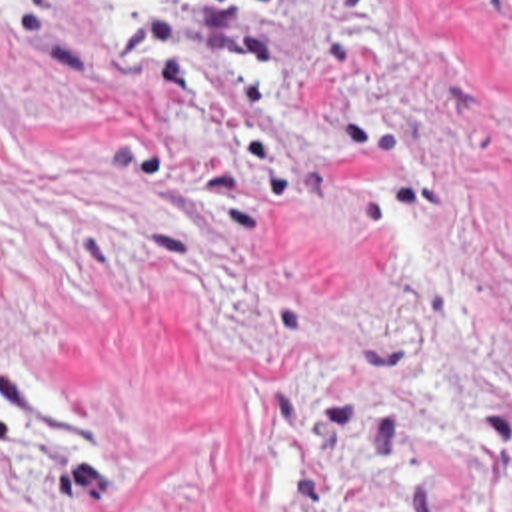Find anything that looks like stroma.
I'll return each instance as SVG.
<instances>
[{
	"instance_id": "obj_1",
	"label": "stroma",
	"mask_w": 512,
	"mask_h": 512,
	"mask_svg": "<svg viewBox=\"0 0 512 512\" xmlns=\"http://www.w3.org/2000/svg\"><path fill=\"white\" fill-rule=\"evenodd\" d=\"M0 512H512V0H0Z\"/></svg>"
}]
</instances>
